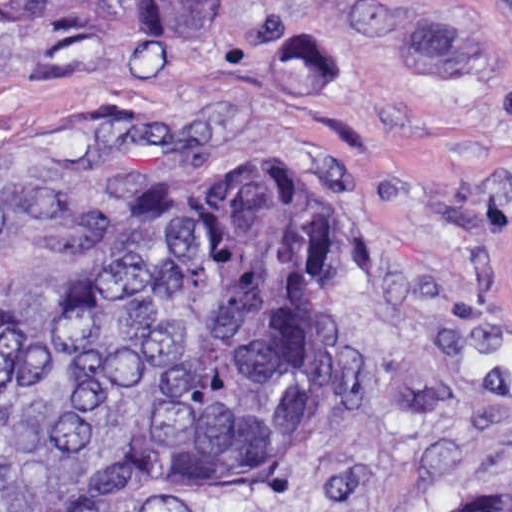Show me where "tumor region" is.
Returning <instances> with one entry per match:
<instances>
[{
  "instance_id": "1",
  "label": "tumor region",
  "mask_w": 512,
  "mask_h": 512,
  "mask_svg": "<svg viewBox=\"0 0 512 512\" xmlns=\"http://www.w3.org/2000/svg\"><path fill=\"white\" fill-rule=\"evenodd\" d=\"M223 0H0L197 45ZM357 384V203L326 148L0 105V512H185L306 478ZM439 512H512V478Z\"/></svg>"
}]
</instances>
